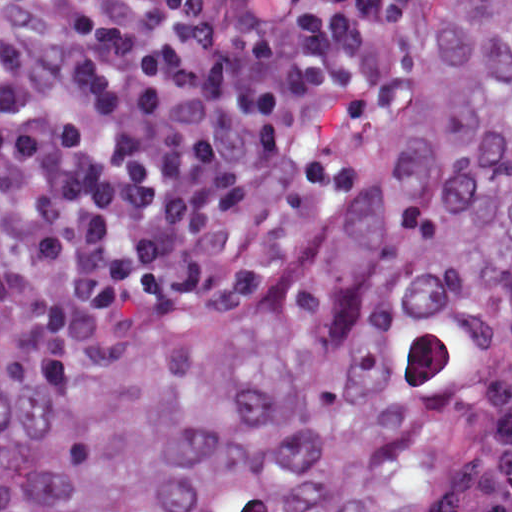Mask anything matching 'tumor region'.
Wrapping results in <instances>:
<instances>
[{"label": "tumor region", "mask_w": 512, "mask_h": 512, "mask_svg": "<svg viewBox=\"0 0 512 512\" xmlns=\"http://www.w3.org/2000/svg\"><path fill=\"white\" fill-rule=\"evenodd\" d=\"M1 512H512V0H435L393 141L257 286L1 282Z\"/></svg>", "instance_id": "1"}]
</instances>
